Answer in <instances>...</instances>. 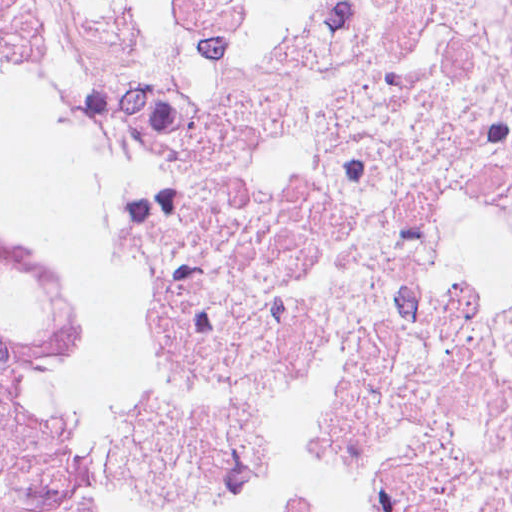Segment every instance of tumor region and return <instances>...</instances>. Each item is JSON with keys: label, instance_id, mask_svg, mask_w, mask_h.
<instances>
[{"label": "tumor region", "instance_id": "obj_1", "mask_svg": "<svg viewBox=\"0 0 512 512\" xmlns=\"http://www.w3.org/2000/svg\"><path fill=\"white\" fill-rule=\"evenodd\" d=\"M70 366V288L0 232V512H76L55 461Z\"/></svg>", "mask_w": 512, "mask_h": 512}]
</instances>
